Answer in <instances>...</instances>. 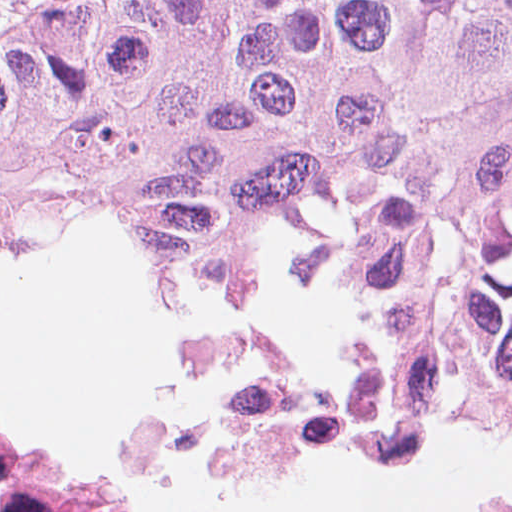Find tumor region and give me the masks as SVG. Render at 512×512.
I'll use <instances>...</instances> for the list:
<instances>
[{"instance_id":"1","label":"tumor region","mask_w":512,"mask_h":512,"mask_svg":"<svg viewBox=\"0 0 512 512\" xmlns=\"http://www.w3.org/2000/svg\"><path fill=\"white\" fill-rule=\"evenodd\" d=\"M338 197L360 334L190 339V377L397 343L512 378V0H70L0 32V266L110 208L145 276L256 296Z\"/></svg>"}]
</instances>
